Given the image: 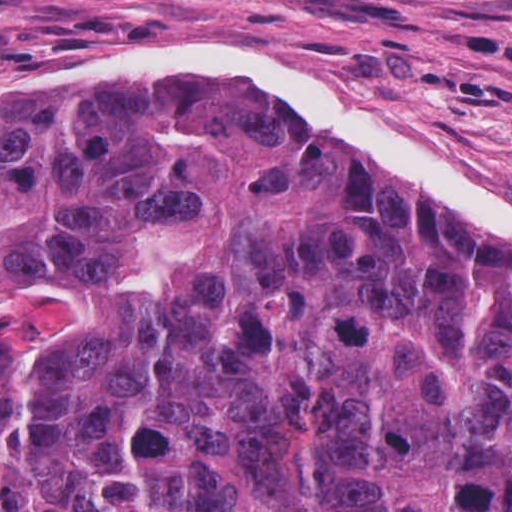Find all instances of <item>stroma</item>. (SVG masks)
I'll return each mask as SVG.
<instances>
[{"label":"stroma","mask_w":512,"mask_h":512,"mask_svg":"<svg viewBox=\"0 0 512 512\" xmlns=\"http://www.w3.org/2000/svg\"><path fill=\"white\" fill-rule=\"evenodd\" d=\"M186 38L251 46L379 107L512 198V0H0V74Z\"/></svg>","instance_id":"1"}]
</instances>
